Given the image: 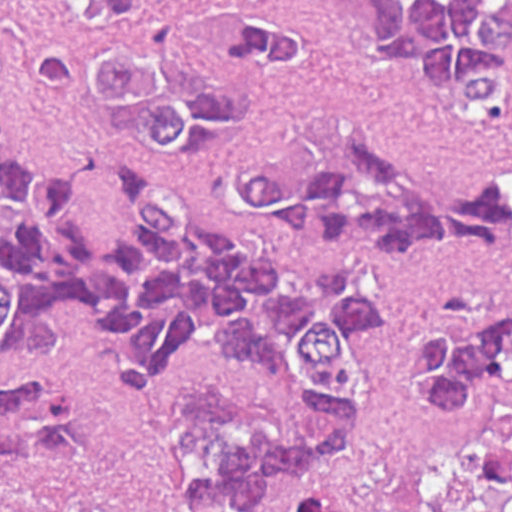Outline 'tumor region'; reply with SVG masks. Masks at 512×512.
<instances>
[{"mask_svg":"<svg viewBox=\"0 0 512 512\" xmlns=\"http://www.w3.org/2000/svg\"><path fill=\"white\" fill-rule=\"evenodd\" d=\"M75 35L32 62L43 93L86 111L150 161L202 163L226 197L278 234L344 248H512V181L392 156L345 114L281 125L262 106L317 66L284 0H63ZM370 60L432 103L512 136V0H342ZM96 165L27 162L0 100V363L64 354L68 304L99 299L135 354L112 374L159 386L192 347L271 373L318 417L285 435L267 404L175 391L167 408L185 490L249 511L276 473L309 470L353 436L371 390L365 332L382 285L359 265L289 278L208 230L163 177L132 165L114 187L118 233L85 232ZM403 373L474 470L482 512H512V292L465 286L413 323ZM0 512H144L108 472L93 386L0 372ZM285 512H354L337 482L293 478Z\"/></svg>","mask_w":512,"mask_h":512,"instance_id":"tumor-region-1","label":"tumor region"}]
</instances>
